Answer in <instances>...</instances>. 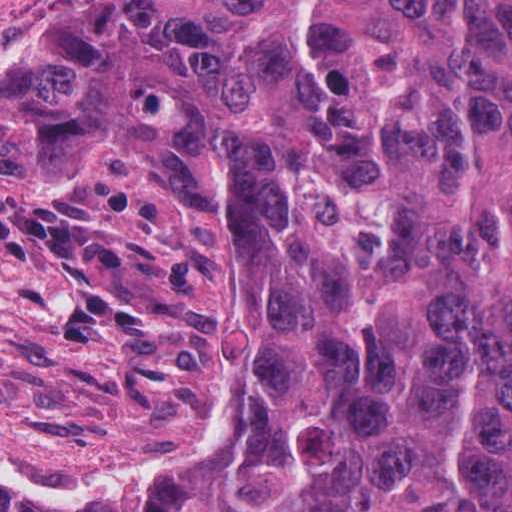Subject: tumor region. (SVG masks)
I'll return each instance as SVG.
<instances>
[{
  "label": "tumor region",
  "instance_id": "e687c5a6",
  "mask_svg": "<svg viewBox=\"0 0 512 512\" xmlns=\"http://www.w3.org/2000/svg\"><path fill=\"white\" fill-rule=\"evenodd\" d=\"M0 159L179 183L268 409L140 508L0 512H512V0H99L0 69Z\"/></svg>",
  "mask_w": 512,
  "mask_h": 512
}]
</instances>
